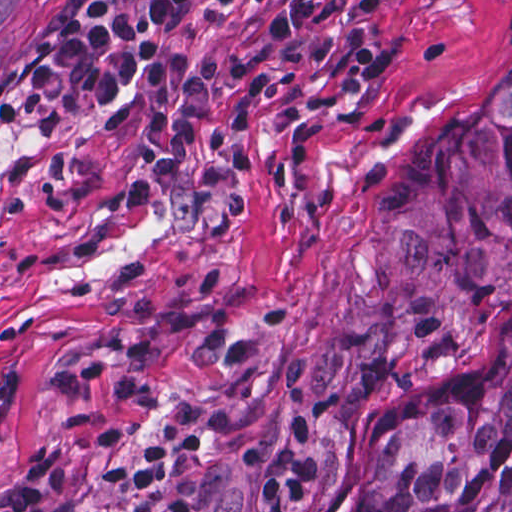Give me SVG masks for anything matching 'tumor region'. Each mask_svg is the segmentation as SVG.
Returning a JSON list of instances; mask_svg holds the SVG:
<instances>
[{
	"mask_svg": "<svg viewBox=\"0 0 512 512\" xmlns=\"http://www.w3.org/2000/svg\"><path fill=\"white\" fill-rule=\"evenodd\" d=\"M512 307V65L379 169L336 310L347 383L447 356ZM342 512H512V351L358 457Z\"/></svg>",
	"mask_w": 512,
	"mask_h": 512,
	"instance_id": "1",
	"label": "tumor region"
}]
</instances>
